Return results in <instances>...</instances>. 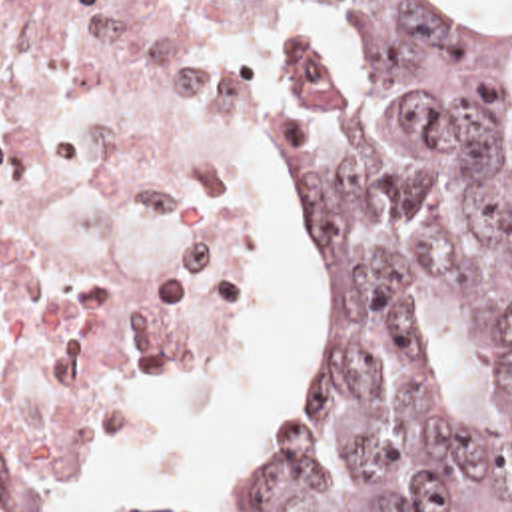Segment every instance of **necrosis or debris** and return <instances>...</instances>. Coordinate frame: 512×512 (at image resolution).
<instances>
[{
    "mask_svg": "<svg viewBox=\"0 0 512 512\" xmlns=\"http://www.w3.org/2000/svg\"><path fill=\"white\" fill-rule=\"evenodd\" d=\"M267 75L223 0H0V512L123 378L237 338Z\"/></svg>",
    "mask_w": 512,
    "mask_h": 512,
    "instance_id": "necrosis-or-debris-1",
    "label": "necrosis or debris"
}]
</instances>
